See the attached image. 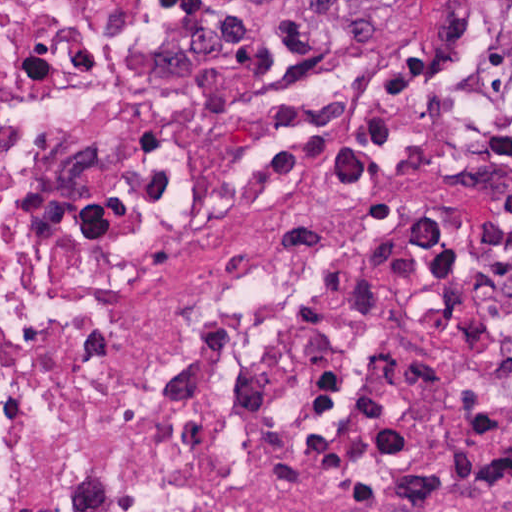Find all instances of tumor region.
I'll list each match as a JSON object with an SVG mask.
<instances>
[{
  "label": "tumor region",
  "instance_id": "obj_1",
  "mask_svg": "<svg viewBox=\"0 0 512 512\" xmlns=\"http://www.w3.org/2000/svg\"><path fill=\"white\" fill-rule=\"evenodd\" d=\"M496 322L498 331L512 350V265L496 280Z\"/></svg>",
  "mask_w": 512,
  "mask_h": 512
}]
</instances>
